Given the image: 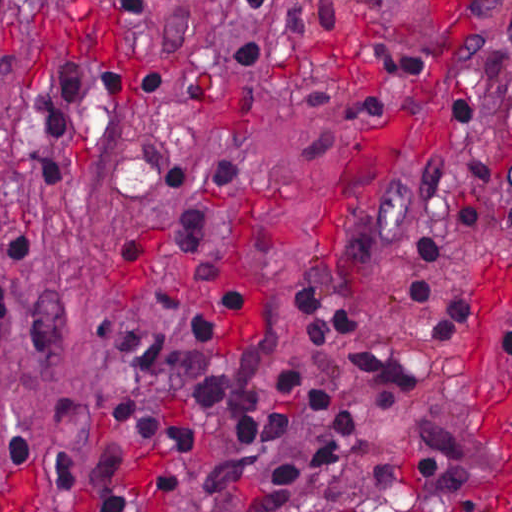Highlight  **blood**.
I'll use <instances>...</instances> for the list:
<instances>
[{"mask_svg": "<svg viewBox=\"0 0 512 512\" xmlns=\"http://www.w3.org/2000/svg\"><path fill=\"white\" fill-rule=\"evenodd\" d=\"M455 8H481L498 0H446ZM511 316L509 351L482 397L483 434L493 460L496 498L512 508V287L508 301ZM0 512H34V473L13 469L0 483Z\"/></svg>", "mask_w": 512, "mask_h": 512, "instance_id": "1", "label": "blood"}]
</instances>
